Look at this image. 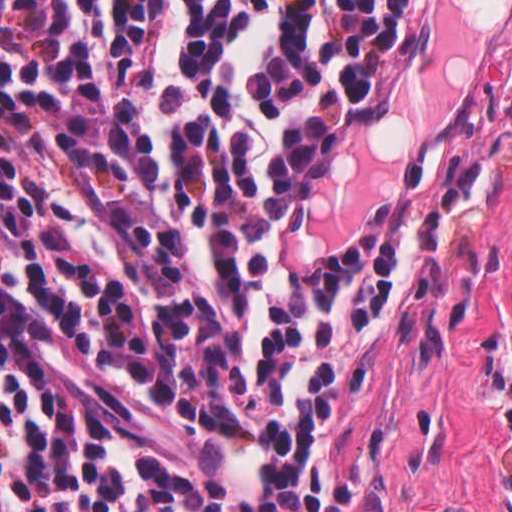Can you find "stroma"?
I'll return each instance as SVG.
<instances>
[{"mask_svg":"<svg viewBox=\"0 0 512 512\" xmlns=\"http://www.w3.org/2000/svg\"><path fill=\"white\" fill-rule=\"evenodd\" d=\"M470 145L486 202L370 332L339 429V512H512V0H439V55L346 125L315 200L363 245L413 159Z\"/></svg>","mask_w":512,"mask_h":512,"instance_id":"35a3bbf8","label":"stroma"}]
</instances>
